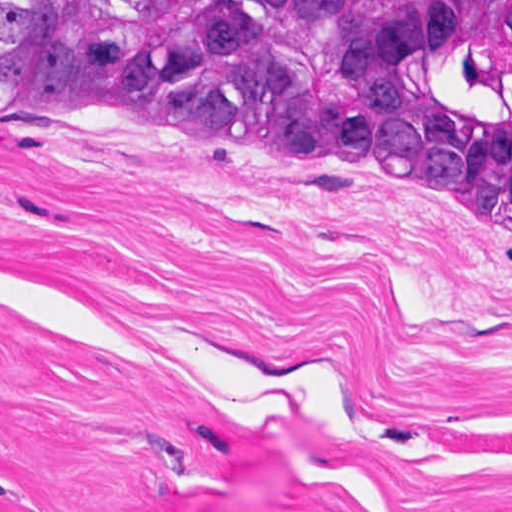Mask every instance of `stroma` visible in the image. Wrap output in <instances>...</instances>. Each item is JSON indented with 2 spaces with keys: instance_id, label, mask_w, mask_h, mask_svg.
<instances>
[{
  "instance_id": "1",
  "label": "stroma",
  "mask_w": 512,
  "mask_h": 512,
  "mask_svg": "<svg viewBox=\"0 0 512 512\" xmlns=\"http://www.w3.org/2000/svg\"><path fill=\"white\" fill-rule=\"evenodd\" d=\"M192 128L0 105V512H512V241Z\"/></svg>"
}]
</instances>
